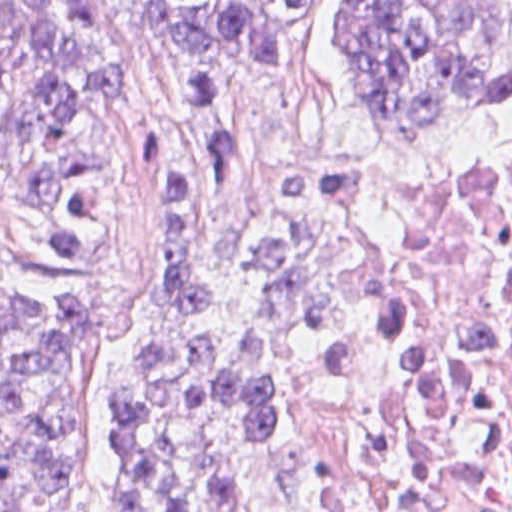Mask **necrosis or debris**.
<instances>
[{
	"mask_svg": "<svg viewBox=\"0 0 512 512\" xmlns=\"http://www.w3.org/2000/svg\"><path fill=\"white\" fill-rule=\"evenodd\" d=\"M302 187L361 301L332 383L352 403L442 398L477 465V498L462 512H512V143L361 159Z\"/></svg>",
	"mask_w": 512,
	"mask_h": 512,
	"instance_id": "necrosis-or-debris-1",
	"label": "necrosis or debris"
}]
</instances>
